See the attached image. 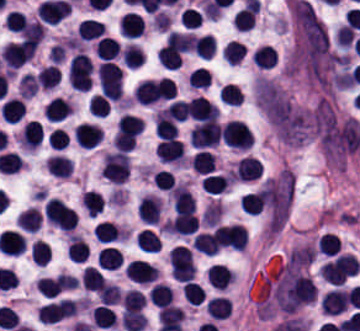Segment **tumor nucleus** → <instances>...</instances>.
<instances>
[{"label": "tumor nucleus", "mask_w": 360, "mask_h": 331, "mask_svg": "<svg viewBox=\"0 0 360 331\" xmlns=\"http://www.w3.org/2000/svg\"><path fill=\"white\" fill-rule=\"evenodd\" d=\"M315 254L316 247L307 242L294 246L286 257V269L307 267L311 264Z\"/></svg>", "instance_id": "obj_1"}]
</instances>
